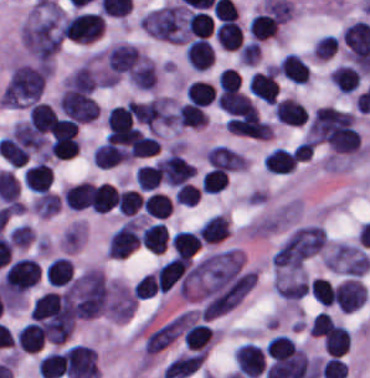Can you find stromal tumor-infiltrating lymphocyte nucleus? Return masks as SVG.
<instances>
[{
    "label": "stromal tumor-infiltrating lymphocyte nucleus",
    "instance_id": "obj_15",
    "mask_svg": "<svg viewBox=\"0 0 370 378\" xmlns=\"http://www.w3.org/2000/svg\"><path fill=\"white\" fill-rule=\"evenodd\" d=\"M126 160L128 148L113 143H100L92 155V163L101 168H111Z\"/></svg>",
    "mask_w": 370,
    "mask_h": 378
},
{
    "label": "stromal tumor-infiltrating lymphocyte nucleus",
    "instance_id": "obj_7",
    "mask_svg": "<svg viewBox=\"0 0 370 378\" xmlns=\"http://www.w3.org/2000/svg\"><path fill=\"white\" fill-rule=\"evenodd\" d=\"M274 117L285 126L300 127L308 118L303 104L292 97H285L273 105Z\"/></svg>",
    "mask_w": 370,
    "mask_h": 378
},
{
    "label": "stromal tumor-infiltrating lymphocyte nucleus",
    "instance_id": "obj_25",
    "mask_svg": "<svg viewBox=\"0 0 370 378\" xmlns=\"http://www.w3.org/2000/svg\"><path fill=\"white\" fill-rule=\"evenodd\" d=\"M159 185L157 163L136 169V187L140 192H152Z\"/></svg>",
    "mask_w": 370,
    "mask_h": 378
},
{
    "label": "stromal tumor-infiltrating lymphocyte nucleus",
    "instance_id": "obj_9",
    "mask_svg": "<svg viewBox=\"0 0 370 378\" xmlns=\"http://www.w3.org/2000/svg\"><path fill=\"white\" fill-rule=\"evenodd\" d=\"M52 171L48 163L35 162L23 172V185L35 193L48 192Z\"/></svg>",
    "mask_w": 370,
    "mask_h": 378
},
{
    "label": "stromal tumor-infiltrating lymphocyte nucleus",
    "instance_id": "obj_14",
    "mask_svg": "<svg viewBox=\"0 0 370 378\" xmlns=\"http://www.w3.org/2000/svg\"><path fill=\"white\" fill-rule=\"evenodd\" d=\"M89 204L95 214H106L116 206V189L108 183L92 184Z\"/></svg>",
    "mask_w": 370,
    "mask_h": 378
},
{
    "label": "stromal tumor-infiltrating lymphocyte nucleus",
    "instance_id": "obj_28",
    "mask_svg": "<svg viewBox=\"0 0 370 378\" xmlns=\"http://www.w3.org/2000/svg\"><path fill=\"white\" fill-rule=\"evenodd\" d=\"M141 200L140 195L131 189H124L117 192V211L120 215H132L139 209Z\"/></svg>",
    "mask_w": 370,
    "mask_h": 378
},
{
    "label": "stromal tumor-infiltrating lymphocyte nucleus",
    "instance_id": "obj_31",
    "mask_svg": "<svg viewBox=\"0 0 370 378\" xmlns=\"http://www.w3.org/2000/svg\"><path fill=\"white\" fill-rule=\"evenodd\" d=\"M156 284L157 279L153 271L144 275L133 285V294L135 298L143 300L154 295Z\"/></svg>",
    "mask_w": 370,
    "mask_h": 378
},
{
    "label": "stromal tumor-infiltrating lymphocyte nucleus",
    "instance_id": "obj_19",
    "mask_svg": "<svg viewBox=\"0 0 370 378\" xmlns=\"http://www.w3.org/2000/svg\"><path fill=\"white\" fill-rule=\"evenodd\" d=\"M201 239L195 230H181L170 238L171 247L178 257H189L197 252Z\"/></svg>",
    "mask_w": 370,
    "mask_h": 378
},
{
    "label": "stromal tumor-infiltrating lymphocyte nucleus",
    "instance_id": "obj_18",
    "mask_svg": "<svg viewBox=\"0 0 370 378\" xmlns=\"http://www.w3.org/2000/svg\"><path fill=\"white\" fill-rule=\"evenodd\" d=\"M91 182L82 180L63 189V203L73 210H82L89 206Z\"/></svg>",
    "mask_w": 370,
    "mask_h": 378
},
{
    "label": "stromal tumor-infiltrating lymphocyte nucleus",
    "instance_id": "obj_34",
    "mask_svg": "<svg viewBox=\"0 0 370 378\" xmlns=\"http://www.w3.org/2000/svg\"><path fill=\"white\" fill-rule=\"evenodd\" d=\"M51 157L69 159L79 153V140L69 142L50 143Z\"/></svg>",
    "mask_w": 370,
    "mask_h": 378
},
{
    "label": "stromal tumor-infiltrating lymphocyte nucleus",
    "instance_id": "obj_29",
    "mask_svg": "<svg viewBox=\"0 0 370 378\" xmlns=\"http://www.w3.org/2000/svg\"><path fill=\"white\" fill-rule=\"evenodd\" d=\"M338 45L336 35L332 33H325L317 39L315 46L312 50L314 59L327 60L331 57Z\"/></svg>",
    "mask_w": 370,
    "mask_h": 378
},
{
    "label": "stromal tumor-infiltrating lymphocyte nucleus",
    "instance_id": "obj_16",
    "mask_svg": "<svg viewBox=\"0 0 370 378\" xmlns=\"http://www.w3.org/2000/svg\"><path fill=\"white\" fill-rule=\"evenodd\" d=\"M215 38L220 47L235 50L243 40V31L236 20H223L215 29Z\"/></svg>",
    "mask_w": 370,
    "mask_h": 378
},
{
    "label": "stromal tumor-infiltrating lymphocyte nucleus",
    "instance_id": "obj_24",
    "mask_svg": "<svg viewBox=\"0 0 370 378\" xmlns=\"http://www.w3.org/2000/svg\"><path fill=\"white\" fill-rule=\"evenodd\" d=\"M178 127H204V115L198 105L183 103L176 109Z\"/></svg>",
    "mask_w": 370,
    "mask_h": 378
},
{
    "label": "stromal tumor-infiltrating lymphocyte nucleus",
    "instance_id": "obj_23",
    "mask_svg": "<svg viewBox=\"0 0 370 378\" xmlns=\"http://www.w3.org/2000/svg\"><path fill=\"white\" fill-rule=\"evenodd\" d=\"M295 353V342L282 335H275L270 338L264 348L265 356L273 360H284Z\"/></svg>",
    "mask_w": 370,
    "mask_h": 378
},
{
    "label": "stromal tumor-infiltrating lymphocyte nucleus",
    "instance_id": "obj_6",
    "mask_svg": "<svg viewBox=\"0 0 370 378\" xmlns=\"http://www.w3.org/2000/svg\"><path fill=\"white\" fill-rule=\"evenodd\" d=\"M228 132L249 137L267 138L270 125L253 116H230L225 124Z\"/></svg>",
    "mask_w": 370,
    "mask_h": 378
},
{
    "label": "stromal tumor-infiltrating lymphocyte nucleus",
    "instance_id": "obj_1",
    "mask_svg": "<svg viewBox=\"0 0 370 378\" xmlns=\"http://www.w3.org/2000/svg\"><path fill=\"white\" fill-rule=\"evenodd\" d=\"M39 277V264L30 258H17L5 272L1 292L9 300H20L36 285Z\"/></svg>",
    "mask_w": 370,
    "mask_h": 378
},
{
    "label": "stromal tumor-infiltrating lymphocyte nucleus",
    "instance_id": "obj_21",
    "mask_svg": "<svg viewBox=\"0 0 370 378\" xmlns=\"http://www.w3.org/2000/svg\"><path fill=\"white\" fill-rule=\"evenodd\" d=\"M172 209V200L169 195L159 191H152L147 194L142 208L143 214L165 219Z\"/></svg>",
    "mask_w": 370,
    "mask_h": 378
},
{
    "label": "stromal tumor-infiltrating lymphocyte nucleus",
    "instance_id": "obj_20",
    "mask_svg": "<svg viewBox=\"0 0 370 378\" xmlns=\"http://www.w3.org/2000/svg\"><path fill=\"white\" fill-rule=\"evenodd\" d=\"M329 81L347 95L357 90V71L351 65L339 64L331 71Z\"/></svg>",
    "mask_w": 370,
    "mask_h": 378
},
{
    "label": "stromal tumor-infiltrating lymphocyte nucleus",
    "instance_id": "obj_26",
    "mask_svg": "<svg viewBox=\"0 0 370 378\" xmlns=\"http://www.w3.org/2000/svg\"><path fill=\"white\" fill-rule=\"evenodd\" d=\"M157 149L156 138L138 131L130 145V157H149L156 153Z\"/></svg>",
    "mask_w": 370,
    "mask_h": 378
},
{
    "label": "stromal tumor-infiltrating lymphocyte nucleus",
    "instance_id": "obj_22",
    "mask_svg": "<svg viewBox=\"0 0 370 378\" xmlns=\"http://www.w3.org/2000/svg\"><path fill=\"white\" fill-rule=\"evenodd\" d=\"M184 96L192 103L204 107L215 101L214 87L205 80H192L186 86Z\"/></svg>",
    "mask_w": 370,
    "mask_h": 378
},
{
    "label": "stromal tumor-infiltrating lymphocyte nucleus",
    "instance_id": "obj_3",
    "mask_svg": "<svg viewBox=\"0 0 370 378\" xmlns=\"http://www.w3.org/2000/svg\"><path fill=\"white\" fill-rule=\"evenodd\" d=\"M235 366L242 378H259L264 369V350L251 342H244L233 352Z\"/></svg>",
    "mask_w": 370,
    "mask_h": 378
},
{
    "label": "stromal tumor-infiltrating lymphocyte nucleus",
    "instance_id": "obj_30",
    "mask_svg": "<svg viewBox=\"0 0 370 378\" xmlns=\"http://www.w3.org/2000/svg\"><path fill=\"white\" fill-rule=\"evenodd\" d=\"M310 288L312 296L320 303L329 306L333 303V290L331 282L321 277H314Z\"/></svg>",
    "mask_w": 370,
    "mask_h": 378
},
{
    "label": "stromal tumor-infiltrating lymphocyte nucleus",
    "instance_id": "obj_17",
    "mask_svg": "<svg viewBox=\"0 0 370 378\" xmlns=\"http://www.w3.org/2000/svg\"><path fill=\"white\" fill-rule=\"evenodd\" d=\"M213 339V328L204 323H191L186 330L184 347L193 351H207Z\"/></svg>",
    "mask_w": 370,
    "mask_h": 378
},
{
    "label": "stromal tumor-infiltrating lymphocyte nucleus",
    "instance_id": "obj_4",
    "mask_svg": "<svg viewBox=\"0 0 370 378\" xmlns=\"http://www.w3.org/2000/svg\"><path fill=\"white\" fill-rule=\"evenodd\" d=\"M248 91L264 104L274 105L279 96L275 70L266 69L250 75Z\"/></svg>",
    "mask_w": 370,
    "mask_h": 378
},
{
    "label": "stromal tumor-infiltrating lymphocyte nucleus",
    "instance_id": "obj_27",
    "mask_svg": "<svg viewBox=\"0 0 370 378\" xmlns=\"http://www.w3.org/2000/svg\"><path fill=\"white\" fill-rule=\"evenodd\" d=\"M228 180V173L225 169L212 167L203 177L201 186L208 194H215L223 190Z\"/></svg>",
    "mask_w": 370,
    "mask_h": 378
},
{
    "label": "stromal tumor-infiltrating lymphocyte nucleus",
    "instance_id": "obj_5",
    "mask_svg": "<svg viewBox=\"0 0 370 378\" xmlns=\"http://www.w3.org/2000/svg\"><path fill=\"white\" fill-rule=\"evenodd\" d=\"M217 102L229 116L258 118L250 98L238 90L223 89L217 95Z\"/></svg>",
    "mask_w": 370,
    "mask_h": 378
},
{
    "label": "stromal tumor-infiltrating lymphocyte nucleus",
    "instance_id": "obj_8",
    "mask_svg": "<svg viewBox=\"0 0 370 378\" xmlns=\"http://www.w3.org/2000/svg\"><path fill=\"white\" fill-rule=\"evenodd\" d=\"M184 55L192 70L204 71L213 62L214 49L205 39L194 38L188 43Z\"/></svg>",
    "mask_w": 370,
    "mask_h": 378
},
{
    "label": "stromal tumor-infiltrating lymphocyte nucleus",
    "instance_id": "obj_32",
    "mask_svg": "<svg viewBox=\"0 0 370 378\" xmlns=\"http://www.w3.org/2000/svg\"><path fill=\"white\" fill-rule=\"evenodd\" d=\"M239 72L233 66H225L218 74V87L221 90L240 88Z\"/></svg>",
    "mask_w": 370,
    "mask_h": 378
},
{
    "label": "stromal tumor-infiltrating lymphocyte nucleus",
    "instance_id": "obj_33",
    "mask_svg": "<svg viewBox=\"0 0 370 378\" xmlns=\"http://www.w3.org/2000/svg\"><path fill=\"white\" fill-rule=\"evenodd\" d=\"M177 204L194 205L200 198V188L192 183H184L174 193Z\"/></svg>",
    "mask_w": 370,
    "mask_h": 378
},
{
    "label": "stromal tumor-infiltrating lymphocyte nucleus",
    "instance_id": "obj_12",
    "mask_svg": "<svg viewBox=\"0 0 370 378\" xmlns=\"http://www.w3.org/2000/svg\"><path fill=\"white\" fill-rule=\"evenodd\" d=\"M276 70L296 85H305L310 77L307 64L295 53H288Z\"/></svg>",
    "mask_w": 370,
    "mask_h": 378
},
{
    "label": "stromal tumor-infiltrating lymphocyte nucleus",
    "instance_id": "obj_11",
    "mask_svg": "<svg viewBox=\"0 0 370 378\" xmlns=\"http://www.w3.org/2000/svg\"><path fill=\"white\" fill-rule=\"evenodd\" d=\"M263 161L266 172L271 174H289L293 171L297 159L294 153L281 147H274L266 152Z\"/></svg>",
    "mask_w": 370,
    "mask_h": 378
},
{
    "label": "stromal tumor-infiltrating lymphocyte nucleus",
    "instance_id": "obj_10",
    "mask_svg": "<svg viewBox=\"0 0 370 378\" xmlns=\"http://www.w3.org/2000/svg\"><path fill=\"white\" fill-rule=\"evenodd\" d=\"M230 231L226 214H213L199 228L198 237L203 245H214Z\"/></svg>",
    "mask_w": 370,
    "mask_h": 378
},
{
    "label": "stromal tumor-infiltrating lymphocyte nucleus",
    "instance_id": "obj_13",
    "mask_svg": "<svg viewBox=\"0 0 370 378\" xmlns=\"http://www.w3.org/2000/svg\"><path fill=\"white\" fill-rule=\"evenodd\" d=\"M168 240V230L164 223L146 225L140 234V244L153 254H162Z\"/></svg>",
    "mask_w": 370,
    "mask_h": 378
},
{
    "label": "stromal tumor-infiltrating lymphocyte nucleus",
    "instance_id": "obj_2",
    "mask_svg": "<svg viewBox=\"0 0 370 378\" xmlns=\"http://www.w3.org/2000/svg\"><path fill=\"white\" fill-rule=\"evenodd\" d=\"M138 244V222L127 218L108 236L106 255L111 259H125Z\"/></svg>",
    "mask_w": 370,
    "mask_h": 378
}]
</instances>
